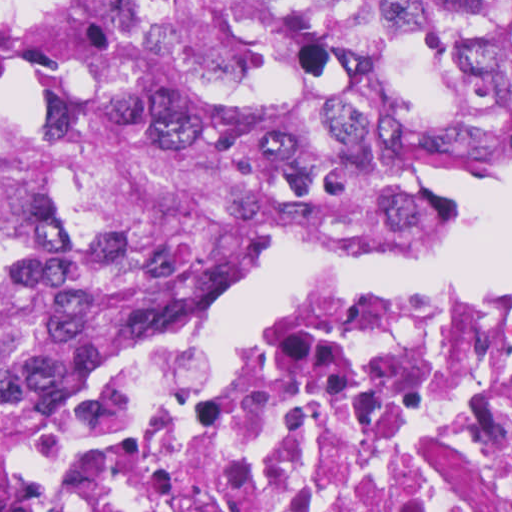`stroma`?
<instances>
[{
    "mask_svg": "<svg viewBox=\"0 0 512 512\" xmlns=\"http://www.w3.org/2000/svg\"><path fill=\"white\" fill-rule=\"evenodd\" d=\"M17 1H512V0H0V6ZM465 187L458 191L459 196ZM362 254L339 243H286L271 254L260 266L279 260L304 255H356ZM259 266V267H260ZM512 280V260L500 267L478 286ZM477 286V287H478ZM193 321V320H192ZM191 322L177 331L188 332ZM262 340V339H261ZM245 343H217L224 348L251 345ZM191 346V345H181ZM90 370H86L69 384L64 406L19 414L0 404V512L18 485L30 459L48 438L54 426L78 393Z\"/></svg>",
    "mask_w": 512,
    "mask_h": 512,
    "instance_id": "stroma-1",
    "label": "stroma"
}]
</instances>
